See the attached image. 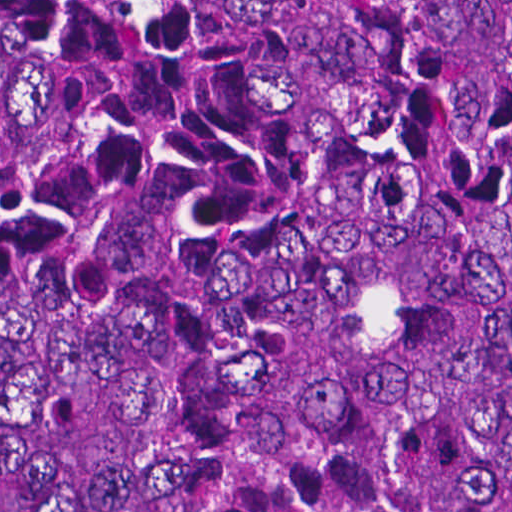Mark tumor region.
<instances>
[{"label":"tumor region","mask_w":512,"mask_h":512,"mask_svg":"<svg viewBox=\"0 0 512 512\" xmlns=\"http://www.w3.org/2000/svg\"><path fill=\"white\" fill-rule=\"evenodd\" d=\"M0 512H512V0H0Z\"/></svg>","instance_id":"1"}]
</instances>
